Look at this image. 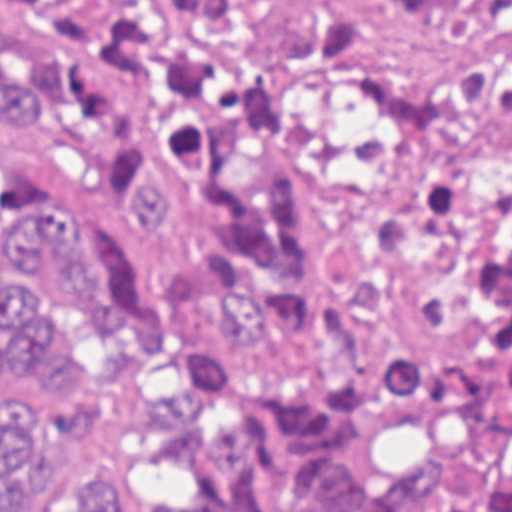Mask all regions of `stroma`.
I'll use <instances>...</instances> for the list:
<instances>
[{
	"label": "stroma",
	"instance_id": "1",
	"mask_svg": "<svg viewBox=\"0 0 512 512\" xmlns=\"http://www.w3.org/2000/svg\"><path fill=\"white\" fill-rule=\"evenodd\" d=\"M178 1L153 97V169L117 192L90 157L49 132L0 143L34 206L88 216L138 260L144 290L177 266L126 231V207L163 180L184 216L205 199L169 149L181 109L230 105L268 124L304 178L322 287L371 260L374 223L460 138L512 132V0ZM111 362L97 419L68 444H40L3 492V512H42L65 478L96 465L122 476L115 512H138V469L165 414L172 372L138 354L134 318L117 331L58 336Z\"/></svg>",
	"mask_w": 512,
	"mask_h": 512
}]
</instances>
